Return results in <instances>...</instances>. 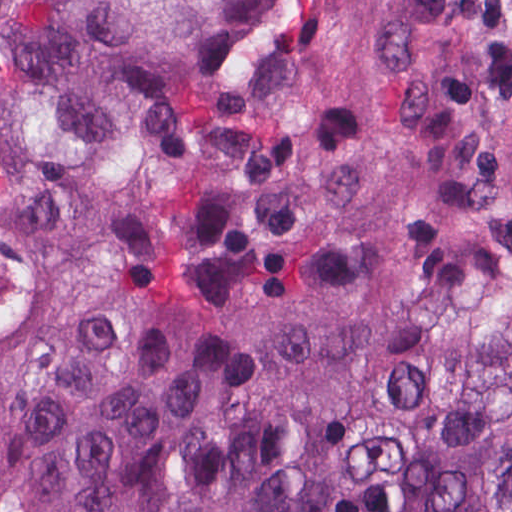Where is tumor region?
I'll list each match as a JSON object with an SVG mask.
<instances>
[{
	"label": "tumor region",
	"instance_id": "1",
	"mask_svg": "<svg viewBox=\"0 0 512 512\" xmlns=\"http://www.w3.org/2000/svg\"><path fill=\"white\" fill-rule=\"evenodd\" d=\"M0 512H512V0H0Z\"/></svg>",
	"mask_w": 512,
	"mask_h": 512
}]
</instances>
